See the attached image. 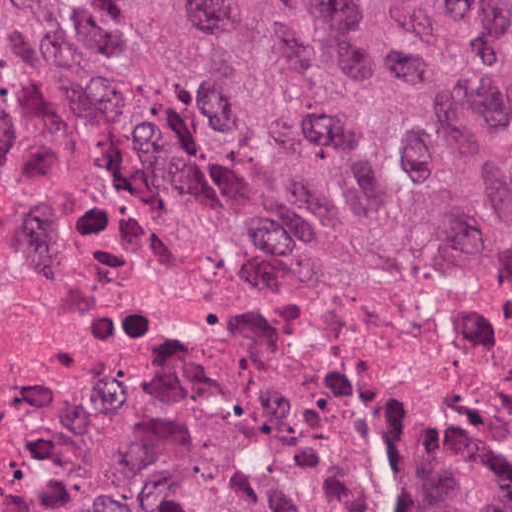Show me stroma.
<instances>
[{
	"instance_id": "stroma-1",
	"label": "stroma",
	"mask_w": 512,
	"mask_h": 512,
	"mask_svg": "<svg viewBox=\"0 0 512 512\" xmlns=\"http://www.w3.org/2000/svg\"><path fill=\"white\" fill-rule=\"evenodd\" d=\"M0 1H512V0H0ZM4 57V54H3ZM5 84V81H4ZM6 86V84H5ZM7 88V87H6ZM111 169V168H108ZM119 174L129 176L138 181L152 185L164 187L167 189L179 191L185 194L200 197L226 206L251 211L262 214L276 221L289 226L297 227L307 231L315 232L337 240L355 242L373 246H381L366 239L343 235L322 225L309 221L307 219L268 212L254 203L250 198L227 191L223 189L184 183L180 181L150 176L140 175L120 170L111 169ZM386 247V246H384ZM441 266V265H440ZM483 266H512V252L505 253ZM393 482L382 483L379 486L376 504L380 512H392V492ZM430 495L433 500L445 508L448 512H465L458 501L454 492L446 488L435 480H425ZM25 500V499H24ZM23 500L0 509L17 505Z\"/></svg>"
}]
</instances>
